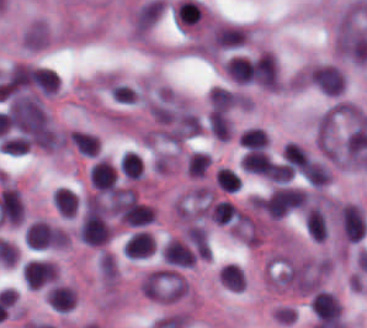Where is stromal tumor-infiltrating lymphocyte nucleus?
<instances>
[{
  "instance_id": "obj_1",
  "label": "stromal tumor-infiltrating lymphocyte nucleus",
  "mask_w": 367,
  "mask_h": 328,
  "mask_svg": "<svg viewBox=\"0 0 367 328\" xmlns=\"http://www.w3.org/2000/svg\"><path fill=\"white\" fill-rule=\"evenodd\" d=\"M283 153L285 162L291 171L311 177L312 162L302 148L294 143H286Z\"/></svg>"
},
{
  "instance_id": "obj_2",
  "label": "stromal tumor-infiltrating lymphocyte nucleus",
  "mask_w": 367,
  "mask_h": 328,
  "mask_svg": "<svg viewBox=\"0 0 367 328\" xmlns=\"http://www.w3.org/2000/svg\"><path fill=\"white\" fill-rule=\"evenodd\" d=\"M154 250L153 237L147 232L138 230L129 235L123 253L131 258L149 255Z\"/></svg>"
},
{
  "instance_id": "obj_3",
  "label": "stromal tumor-infiltrating lymphocyte nucleus",
  "mask_w": 367,
  "mask_h": 328,
  "mask_svg": "<svg viewBox=\"0 0 367 328\" xmlns=\"http://www.w3.org/2000/svg\"><path fill=\"white\" fill-rule=\"evenodd\" d=\"M115 172L106 159H99L89 169V181L99 191H107L115 179Z\"/></svg>"
},
{
  "instance_id": "obj_4",
  "label": "stromal tumor-infiltrating lymphocyte nucleus",
  "mask_w": 367,
  "mask_h": 328,
  "mask_svg": "<svg viewBox=\"0 0 367 328\" xmlns=\"http://www.w3.org/2000/svg\"><path fill=\"white\" fill-rule=\"evenodd\" d=\"M247 34L240 28L218 27L212 33L211 44L214 47H239L246 39Z\"/></svg>"
},
{
  "instance_id": "obj_5",
  "label": "stromal tumor-infiltrating lymphocyte nucleus",
  "mask_w": 367,
  "mask_h": 328,
  "mask_svg": "<svg viewBox=\"0 0 367 328\" xmlns=\"http://www.w3.org/2000/svg\"><path fill=\"white\" fill-rule=\"evenodd\" d=\"M242 167L251 173L270 175L274 165L273 162L261 151L248 149L241 160Z\"/></svg>"
},
{
  "instance_id": "obj_6",
  "label": "stromal tumor-infiltrating lymphocyte nucleus",
  "mask_w": 367,
  "mask_h": 328,
  "mask_svg": "<svg viewBox=\"0 0 367 328\" xmlns=\"http://www.w3.org/2000/svg\"><path fill=\"white\" fill-rule=\"evenodd\" d=\"M154 218L153 210L149 205L136 200L126 203L121 219L127 224H147Z\"/></svg>"
},
{
  "instance_id": "obj_7",
  "label": "stromal tumor-infiltrating lymphocyte nucleus",
  "mask_w": 367,
  "mask_h": 328,
  "mask_svg": "<svg viewBox=\"0 0 367 328\" xmlns=\"http://www.w3.org/2000/svg\"><path fill=\"white\" fill-rule=\"evenodd\" d=\"M46 298L53 307L68 311L74 305L75 293L68 285L53 284L49 287Z\"/></svg>"
},
{
  "instance_id": "obj_8",
  "label": "stromal tumor-infiltrating lymphocyte nucleus",
  "mask_w": 367,
  "mask_h": 328,
  "mask_svg": "<svg viewBox=\"0 0 367 328\" xmlns=\"http://www.w3.org/2000/svg\"><path fill=\"white\" fill-rule=\"evenodd\" d=\"M305 225L313 240L324 241L327 233L326 221L316 205L306 211Z\"/></svg>"
},
{
  "instance_id": "obj_9",
  "label": "stromal tumor-infiltrating lymphocyte nucleus",
  "mask_w": 367,
  "mask_h": 328,
  "mask_svg": "<svg viewBox=\"0 0 367 328\" xmlns=\"http://www.w3.org/2000/svg\"><path fill=\"white\" fill-rule=\"evenodd\" d=\"M232 79L242 82L253 81L252 63L240 55H233L225 66Z\"/></svg>"
},
{
  "instance_id": "obj_10",
  "label": "stromal tumor-infiltrating lymphocyte nucleus",
  "mask_w": 367,
  "mask_h": 328,
  "mask_svg": "<svg viewBox=\"0 0 367 328\" xmlns=\"http://www.w3.org/2000/svg\"><path fill=\"white\" fill-rule=\"evenodd\" d=\"M78 199L74 192L65 187H58L54 191V207L63 217H73Z\"/></svg>"
},
{
  "instance_id": "obj_11",
  "label": "stromal tumor-infiltrating lymphocyte nucleus",
  "mask_w": 367,
  "mask_h": 328,
  "mask_svg": "<svg viewBox=\"0 0 367 328\" xmlns=\"http://www.w3.org/2000/svg\"><path fill=\"white\" fill-rule=\"evenodd\" d=\"M237 96L232 90L214 86L209 94L210 106L214 111H223L236 102Z\"/></svg>"
},
{
  "instance_id": "obj_12",
  "label": "stromal tumor-infiltrating lymphocyte nucleus",
  "mask_w": 367,
  "mask_h": 328,
  "mask_svg": "<svg viewBox=\"0 0 367 328\" xmlns=\"http://www.w3.org/2000/svg\"><path fill=\"white\" fill-rule=\"evenodd\" d=\"M207 120L215 137L228 139L231 134V128L226 112L210 110L207 115Z\"/></svg>"
},
{
  "instance_id": "obj_13",
  "label": "stromal tumor-infiltrating lymphocyte nucleus",
  "mask_w": 367,
  "mask_h": 328,
  "mask_svg": "<svg viewBox=\"0 0 367 328\" xmlns=\"http://www.w3.org/2000/svg\"><path fill=\"white\" fill-rule=\"evenodd\" d=\"M120 170L127 177L139 178L142 175V164L138 153L125 150L119 160Z\"/></svg>"
},
{
  "instance_id": "obj_14",
  "label": "stromal tumor-infiltrating lymphocyte nucleus",
  "mask_w": 367,
  "mask_h": 328,
  "mask_svg": "<svg viewBox=\"0 0 367 328\" xmlns=\"http://www.w3.org/2000/svg\"><path fill=\"white\" fill-rule=\"evenodd\" d=\"M69 139L83 154L95 155L97 152V136L92 133L72 131Z\"/></svg>"
},
{
  "instance_id": "obj_15",
  "label": "stromal tumor-infiltrating lymphocyte nucleus",
  "mask_w": 367,
  "mask_h": 328,
  "mask_svg": "<svg viewBox=\"0 0 367 328\" xmlns=\"http://www.w3.org/2000/svg\"><path fill=\"white\" fill-rule=\"evenodd\" d=\"M211 155L195 151L186 158V170L191 176H202L205 174Z\"/></svg>"
},
{
  "instance_id": "obj_16",
  "label": "stromal tumor-infiltrating lymphocyte nucleus",
  "mask_w": 367,
  "mask_h": 328,
  "mask_svg": "<svg viewBox=\"0 0 367 328\" xmlns=\"http://www.w3.org/2000/svg\"><path fill=\"white\" fill-rule=\"evenodd\" d=\"M59 77L52 68H37V87L42 93L57 90Z\"/></svg>"
},
{
  "instance_id": "obj_17",
  "label": "stromal tumor-infiltrating lymphocyte nucleus",
  "mask_w": 367,
  "mask_h": 328,
  "mask_svg": "<svg viewBox=\"0 0 367 328\" xmlns=\"http://www.w3.org/2000/svg\"><path fill=\"white\" fill-rule=\"evenodd\" d=\"M238 139L241 144L248 148H263L266 144L264 129L248 127L239 133Z\"/></svg>"
},
{
  "instance_id": "obj_18",
  "label": "stromal tumor-infiltrating lymphocyte nucleus",
  "mask_w": 367,
  "mask_h": 328,
  "mask_svg": "<svg viewBox=\"0 0 367 328\" xmlns=\"http://www.w3.org/2000/svg\"><path fill=\"white\" fill-rule=\"evenodd\" d=\"M216 177L223 190L236 191L240 185L236 173L227 166H220Z\"/></svg>"
}]
</instances>
